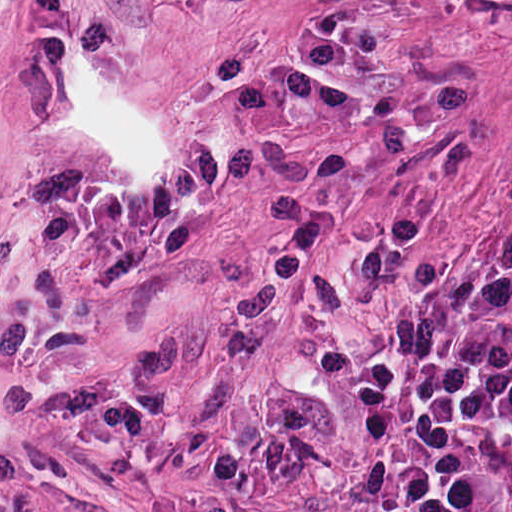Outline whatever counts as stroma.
Here are the masks:
<instances>
[{
	"label": "stroma",
	"instance_id": "stroma-1",
	"mask_svg": "<svg viewBox=\"0 0 512 512\" xmlns=\"http://www.w3.org/2000/svg\"><path fill=\"white\" fill-rule=\"evenodd\" d=\"M512 247V0H384L217 512H400L415 310Z\"/></svg>",
	"mask_w": 512,
	"mask_h": 512
}]
</instances>
